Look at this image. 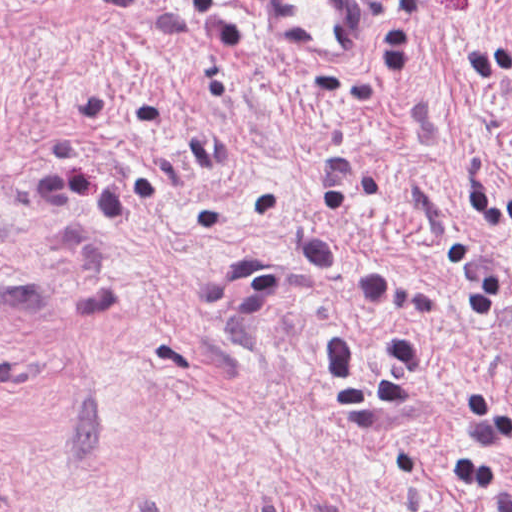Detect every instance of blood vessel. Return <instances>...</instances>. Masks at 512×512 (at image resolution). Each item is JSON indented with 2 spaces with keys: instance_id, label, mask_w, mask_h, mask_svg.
I'll use <instances>...</instances> for the list:
<instances>
[{
  "instance_id": "1",
  "label": "blood vessel",
  "mask_w": 512,
  "mask_h": 512,
  "mask_svg": "<svg viewBox=\"0 0 512 512\" xmlns=\"http://www.w3.org/2000/svg\"><path fill=\"white\" fill-rule=\"evenodd\" d=\"M278 37L313 60H349L367 49L376 17L358 0H258Z\"/></svg>"
}]
</instances>
